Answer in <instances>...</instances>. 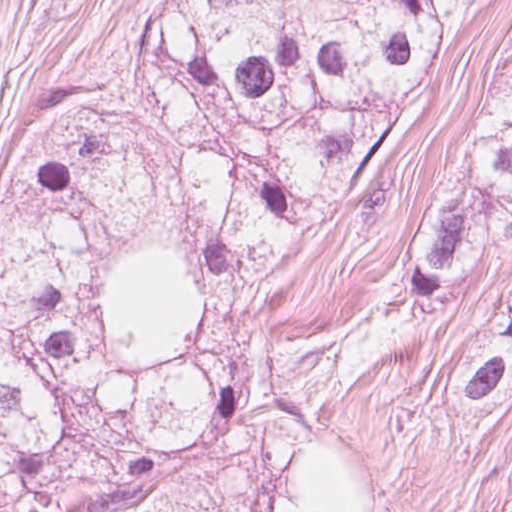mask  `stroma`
I'll use <instances>...</instances> for the list:
<instances>
[{"mask_svg":"<svg viewBox=\"0 0 512 512\" xmlns=\"http://www.w3.org/2000/svg\"><path fill=\"white\" fill-rule=\"evenodd\" d=\"M158 0H0V225L11 175L48 116L129 63ZM512 51V0L458 20L409 146L371 172L337 219L280 266L263 296L274 338H305L402 273L466 162ZM512 292L496 276L454 299L410 367L351 394L346 418L390 492V512H512V400L458 430L452 404L484 320Z\"/></svg>","mask_w":512,"mask_h":512,"instance_id":"35a3bbf8","label":"stroma"}]
</instances>
